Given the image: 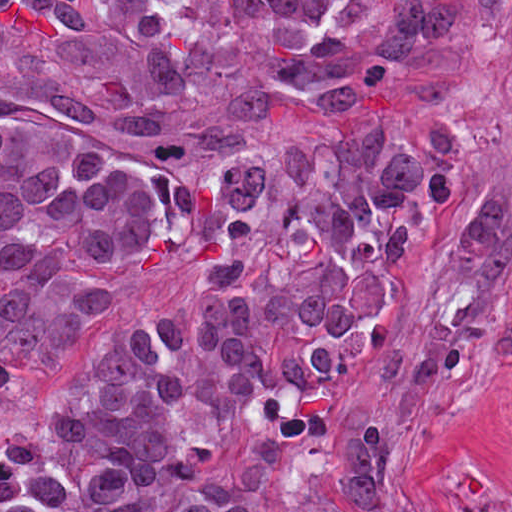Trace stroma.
<instances>
[{
    "instance_id": "35a3bbf8",
    "label": "stroma",
    "mask_w": 512,
    "mask_h": 512,
    "mask_svg": "<svg viewBox=\"0 0 512 512\" xmlns=\"http://www.w3.org/2000/svg\"><path fill=\"white\" fill-rule=\"evenodd\" d=\"M487 141L485 197L496 196L512 214V101L504 91L468 107ZM416 263L405 292L366 337L363 376L366 391L388 421L421 439L438 458L444 512L464 486L512 484V335L487 355L421 390H398L376 370V351L405 332L426 300L431 272L449 239Z\"/></svg>"
}]
</instances>
